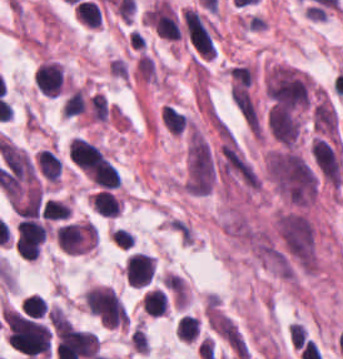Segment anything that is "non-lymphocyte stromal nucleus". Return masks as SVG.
<instances>
[{
    "instance_id": "obj_1",
    "label": "non-lymphocyte stromal nucleus",
    "mask_w": 343,
    "mask_h": 359,
    "mask_svg": "<svg viewBox=\"0 0 343 359\" xmlns=\"http://www.w3.org/2000/svg\"><path fill=\"white\" fill-rule=\"evenodd\" d=\"M215 177L214 157L204 139L190 133L185 155L184 187L191 196H204Z\"/></svg>"
},
{
    "instance_id": "obj_2",
    "label": "non-lymphocyte stromal nucleus",
    "mask_w": 343,
    "mask_h": 359,
    "mask_svg": "<svg viewBox=\"0 0 343 359\" xmlns=\"http://www.w3.org/2000/svg\"><path fill=\"white\" fill-rule=\"evenodd\" d=\"M185 36L201 58H211L215 54L214 43L200 17L191 8L181 12Z\"/></svg>"
}]
</instances>
